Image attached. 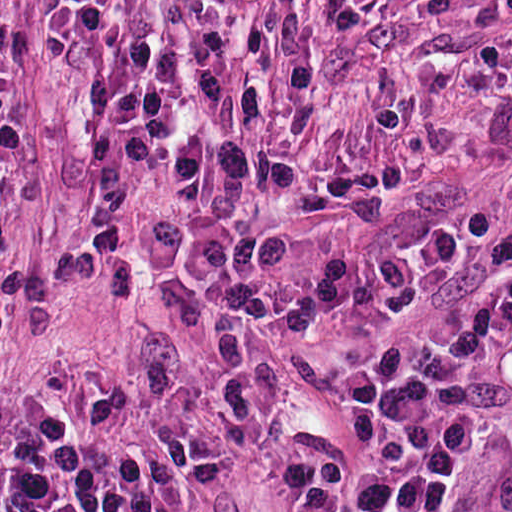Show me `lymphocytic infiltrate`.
<instances>
[{
	"instance_id": "f902f5d3",
	"label": "lymphocytic infiltrate",
	"mask_w": 512,
	"mask_h": 512,
	"mask_svg": "<svg viewBox=\"0 0 512 512\" xmlns=\"http://www.w3.org/2000/svg\"><path fill=\"white\" fill-rule=\"evenodd\" d=\"M512 368V265L473 305L393 329L361 367L367 435L304 434L280 460L317 512H438L462 462L472 391ZM227 462L192 433L154 455L101 462L64 418L41 412L15 441L7 512H185Z\"/></svg>"
}]
</instances>
